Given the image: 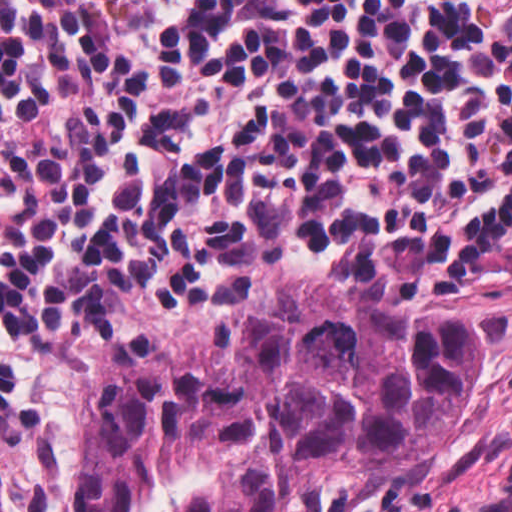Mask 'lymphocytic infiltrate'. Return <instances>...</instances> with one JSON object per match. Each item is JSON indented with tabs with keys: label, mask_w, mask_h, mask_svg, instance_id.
Listing matches in <instances>:
<instances>
[{
	"label": "lymphocytic infiltrate",
	"mask_w": 512,
	"mask_h": 512,
	"mask_svg": "<svg viewBox=\"0 0 512 512\" xmlns=\"http://www.w3.org/2000/svg\"><path fill=\"white\" fill-rule=\"evenodd\" d=\"M510 263L512 0H0V512L59 511L99 323Z\"/></svg>",
	"instance_id": "obj_1"
}]
</instances>
